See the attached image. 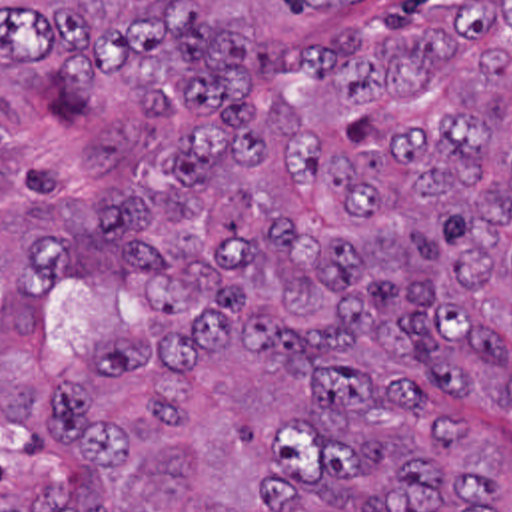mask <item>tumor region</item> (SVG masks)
I'll use <instances>...</instances> for the list:
<instances>
[{
	"label": "tumor region",
	"mask_w": 512,
	"mask_h": 512,
	"mask_svg": "<svg viewBox=\"0 0 512 512\" xmlns=\"http://www.w3.org/2000/svg\"><path fill=\"white\" fill-rule=\"evenodd\" d=\"M512 0H0V512H503Z\"/></svg>",
	"instance_id": "1"
}]
</instances>
